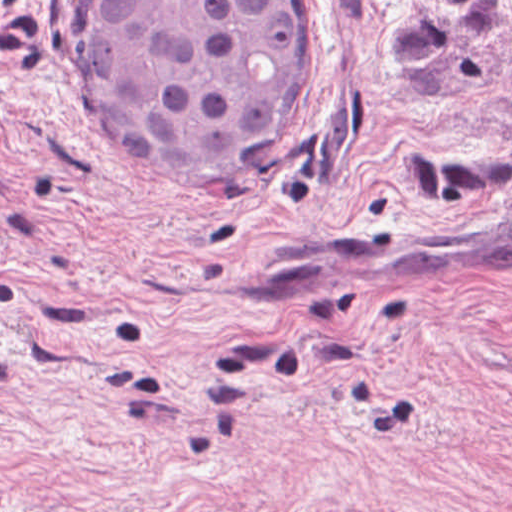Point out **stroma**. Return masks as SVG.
Listing matches in <instances>:
<instances>
[{"label":"stroma","mask_w":512,"mask_h":512,"mask_svg":"<svg viewBox=\"0 0 512 512\" xmlns=\"http://www.w3.org/2000/svg\"><path fill=\"white\" fill-rule=\"evenodd\" d=\"M268 176L133 152L99 0H0V512H512V0H313Z\"/></svg>","instance_id":"stroma-1"}]
</instances>
